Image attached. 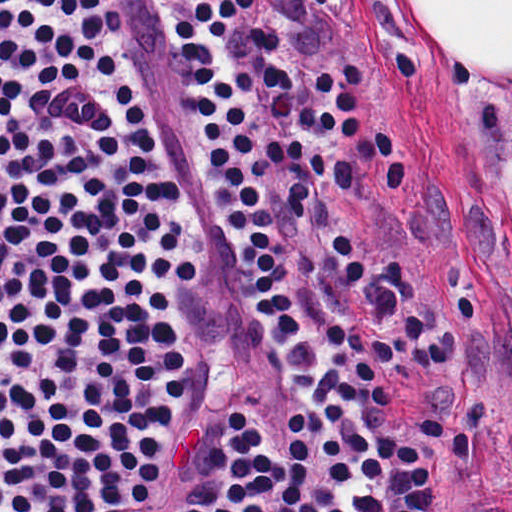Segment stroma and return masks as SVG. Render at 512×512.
Returning <instances> with one entry per match:
<instances>
[{"label":"stroma","mask_w":512,"mask_h":512,"mask_svg":"<svg viewBox=\"0 0 512 512\" xmlns=\"http://www.w3.org/2000/svg\"><path fill=\"white\" fill-rule=\"evenodd\" d=\"M316 15L261 0L257 18L279 35L296 78L299 111L316 72L332 63L366 70L363 134L377 128L403 157L405 189L386 192L368 164L338 199L384 263L400 258L419 311L435 312L448 369L390 390L389 424L419 446L437 490V512H512V277L506 235L489 187V162L512 72L440 51L408 0H328ZM180 0H150L154 48L166 106L172 176L181 185V225L201 262L196 286H168L125 271L100 246L71 253L99 258L169 297L192 361L197 422L216 430L226 404L277 413L287 465V415L302 404L309 423L310 497L324 512L326 427L296 393L277 335L258 321L249 275L214 204L200 149L195 92L172 39ZM172 191L174 192L173 182ZM175 194V193H174ZM176 200V199H175ZM255 451L217 432L200 477L226 454Z\"/></svg>","instance_id":"35a3bbf8"}]
</instances>
